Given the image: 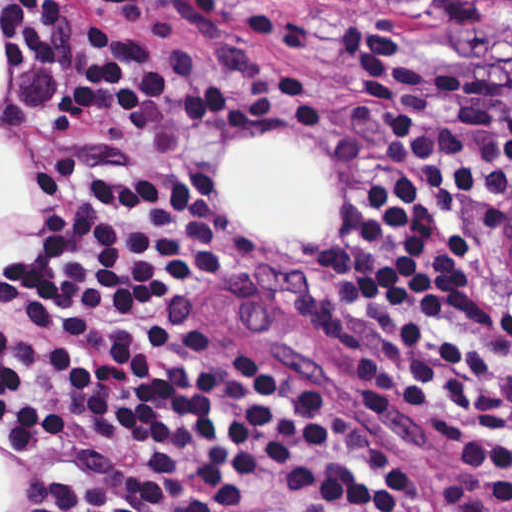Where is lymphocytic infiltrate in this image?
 <instances>
[{
  "label": "lymphocytic infiltrate",
  "instance_id": "f902f5d3",
  "mask_svg": "<svg viewBox=\"0 0 512 512\" xmlns=\"http://www.w3.org/2000/svg\"><path fill=\"white\" fill-rule=\"evenodd\" d=\"M1 31V150L46 173L40 225L1 262V449L21 512H433L329 384L173 321L212 257L214 205L189 176L150 172L259 113V47L199 0H1ZM336 47L384 134L336 245L341 349L512 480V357L472 319L474 240L512 191V85L348 6Z\"/></svg>",
  "mask_w": 512,
  "mask_h": 512
}]
</instances>
